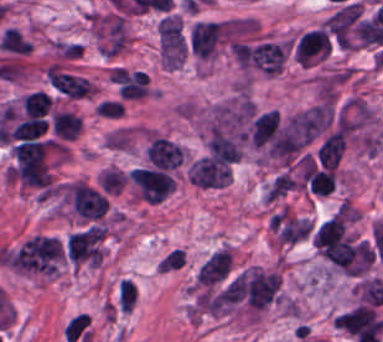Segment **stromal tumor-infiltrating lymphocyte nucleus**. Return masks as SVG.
<instances>
[{
    "mask_svg": "<svg viewBox=\"0 0 383 342\" xmlns=\"http://www.w3.org/2000/svg\"><path fill=\"white\" fill-rule=\"evenodd\" d=\"M333 43L324 27L306 31L295 42L293 49L298 62H317L328 56Z\"/></svg>",
    "mask_w": 383,
    "mask_h": 342,
    "instance_id": "stromal-tumor-infiltrating-lymphocyte-nucleus-2",
    "label": "stromal tumor-infiltrating lymphocyte nucleus"
},
{
    "mask_svg": "<svg viewBox=\"0 0 383 342\" xmlns=\"http://www.w3.org/2000/svg\"><path fill=\"white\" fill-rule=\"evenodd\" d=\"M48 120L39 115H30L13 126L8 136L12 139H32L46 130Z\"/></svg>",
    "mask_w": 383,
    "mask_h": 342,
    "instance_id": "stromal-tumor-infiltrating-lymphocyte-nucleus-5",
    "label": "stromal tumor-infiltrating lymphocyte nucleus"
},
{
    "mask_svg": "<svg viewBox=\"0 0 383 342\" xmlns=\"http://www.w3.org/2000/svg\"><path fill=\"white\" fill-rule=\"evenodd\" d=\"M47 76L51 85L71 98L85 96L95 87L86 78L56 67H49Z\"/></svg>",
    "mask_w": 383,
    "mask_h": 342,
    "instance_id": "stromal-tumor-infiltrating-lymphocyte-nucleus-4",
    "label": "stromal tumor-infiltrating lymphocyte nucleus"
},
{
    "mask_svg": "<svg viewBox=\"0 0 383 342\" xmlns=\"http://www.w3.org/2000/svg\"><path fill=\"white\" fill-rule=\"evenodd\" d=\"M147 154L148 159L158 169H174L183 161L182 146L159 135L148 147Z\"/></svg>",
    "mask_w": 383,
    "mask_h": 342,
    "instance_id": "stromal-tumor-infiltrating-lymphocyte-nucleus-3",
    "label": "stromal tumor-infiltrating lymphocyte nucleus"
},
{
    "mask_svg": "<svg viewBox=\"0 0 383 342\" xmlns=\"http://www.w3.org/2000/svg\"><path fill=\"white\" fill-rule=\"evenodd\" d=\"M23 106L27 116L45 114L50 110L51 97L43 89H35L23 96Z\"/></svg>",
    "mask_w": 383,
    "mask_h": 342,
    "instance_id": "stromal-tumor-infiltrating-lymphocyte-nucleus-6",
    "label": "stromal tumor-infiltrating lymphocyte nucleus"
},
{
    "mask_svg": "<svg viewBox=\"0 0 383 342\" xmlns=\"http://www.w3.org/2000/svg\"><path fill=\"white\" fill-rule=\"evenodd\" d=\"M72 204L86 218H98L105 213L107 201L101 193L84 181L66 186Z\"/></svg>",
    "mask_w": 383,
    "mask_h": 342,
    "instance_id": "stromal-tumor-infiltrating-lymphocyte-nucleus-1",
    "label": "stromal tumor-infiltrating lymphocyte nucleus"
}]
</instances>
